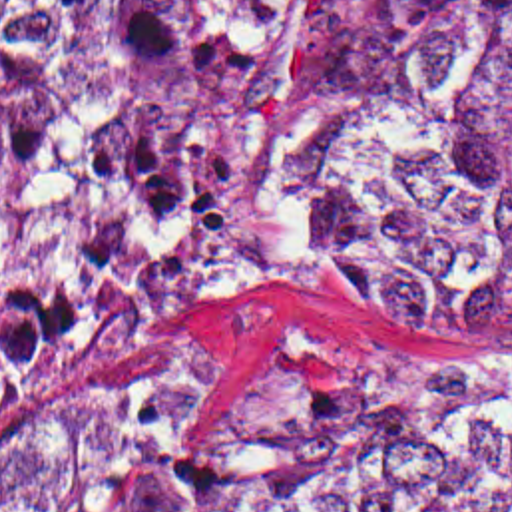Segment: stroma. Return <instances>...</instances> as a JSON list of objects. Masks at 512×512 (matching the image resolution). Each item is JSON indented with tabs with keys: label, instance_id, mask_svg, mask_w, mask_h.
Listing matches in <instances>:
<instances>
[{
	"label": "stroma",
	"instance_id": "1",
	"mask_svg": "<svg viewBox=\"0 0 512 512\" xmlns=\"http://www.w3.org/2000/svg\"><path fill=\"white\" fill-rule=\"evenodd\" d=\"M424 157V192L315 252H279L255 224V173L269 133L321 99H359ZM442 185L418 137L363 63V0H295L225 113V280L133 344L72 374L44 404L0 424V465L34 459L60 422L143 364L187 354L177 445L215 465L253 424L261 392H426L476 380L512 346L450 308L319 264L341 242L424 208Z\"/></svg>",
	"mask_w": 512,
	"mask_h": 512
}]
</instances>
